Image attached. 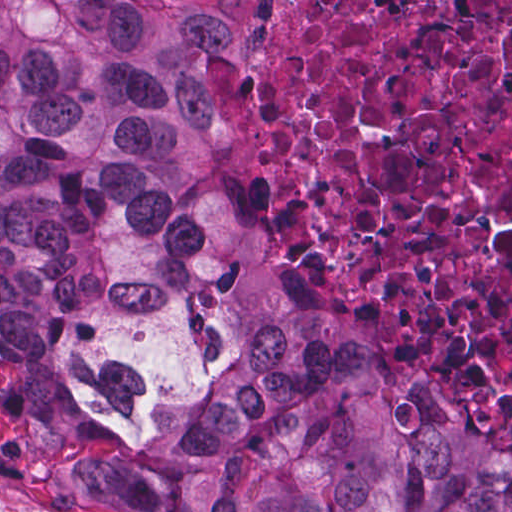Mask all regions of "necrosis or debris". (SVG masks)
<instances>
[{
    "instance_id": "1",
    "label": "necrosis or debris",
    "mask_w": 512,
    "mask_h": 512,
    "mask_svg": "<svg viewBox=\"0 0 512 512\" xmlns=\"http://www.w3.org/2000/svg\"><path fill=\"white\" fill-rule=\"evenodd\" d=\"M213 91L221 172L326 245L368 335L512 420V0H271Z\"/></svg>"
}]
</instances>
